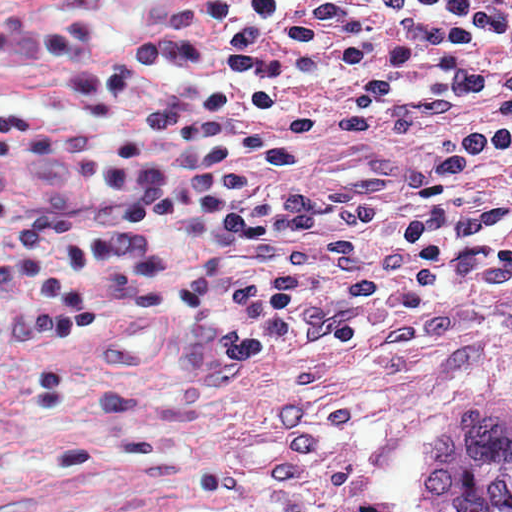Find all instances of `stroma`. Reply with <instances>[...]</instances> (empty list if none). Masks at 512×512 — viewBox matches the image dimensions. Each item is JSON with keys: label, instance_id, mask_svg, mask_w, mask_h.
Segmentation results:
<instances>
[{"label": "stroma", "instance_id": "1", "mask_svg": "<svg viewBox=\"0 0 512 512\" xmlns=\"http://www.w3.org/2000/svg\"><path fill=\"white\" fill-rule=\"evenodd\" d=\"M210 1L22 0L87 148L146 108L227 89ZM361 79L293 99L313 132L277 193L303 197L461 144L512 103L509 79L374 122L347 104ZM124 233L250 512H428L422 469L456 404L512 396V264L440 280L411 304L360 317L339 343L286 333L225 379L194 380L189 280L224 247V229L153 220Z\"/></svg>", "mask_w": 512, "mask_h": 512}]
</instances>
